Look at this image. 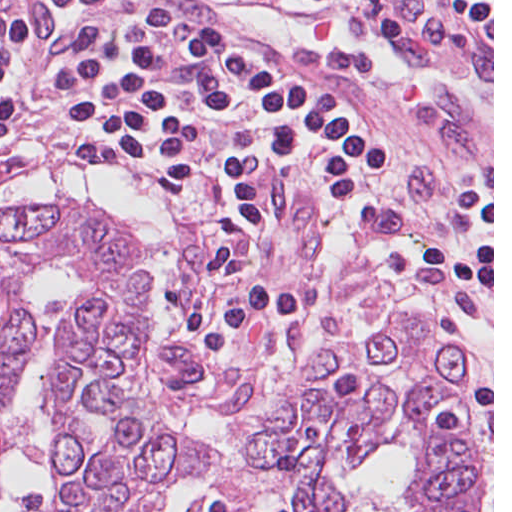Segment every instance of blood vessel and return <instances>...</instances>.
Here are the masks:
<instances>
[{
	"label": "blood vessel",
	"mask_w": 512,
	"mask_h": 512,
	"mask_svg": "<svg viewBox=\"0 0 512 512\" xmlns=\"http://www.w3.org/2000/svg\"><path fill=\"white\" fill-rule=\"evenodd\" d=\"M114 0H58L56 16L44 21L35 16L22 17L25 28H32Z\"/></svg>",
	"instance_id": "obj_1"
}]
</instances>
